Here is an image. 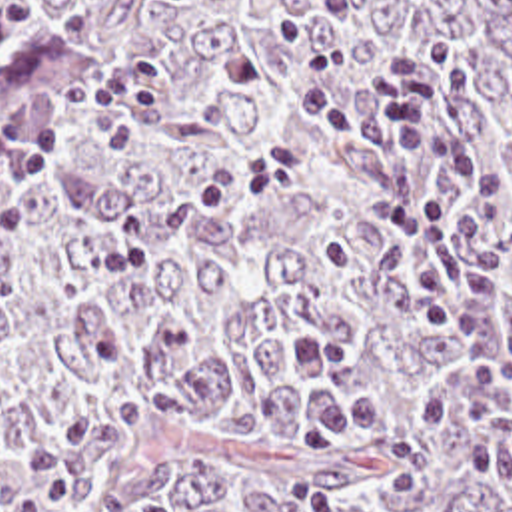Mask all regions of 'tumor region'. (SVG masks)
<instances>
[{
    "mask_svg": "<svg viewBox=\"0 0 512 512\" xmlns=\"http://www.w3.org/2000/svg\"><path fill=\"white\" fill-rule=\"evenodd\" d=\"M357 4L351 102L427 38L473 66L419 162L507 176L512 326V0ZM283 20L337 34L313 0H0V512H55L49 440L77 512H512V462L419 416L455 336L367 218L375 150L297 112Z\"/></svg>",
    "mask_w": 512,
    "mask_h": 512,
    "instance_id": "e687c5a6",
    "label": "tumor region"
}]
</instances>
